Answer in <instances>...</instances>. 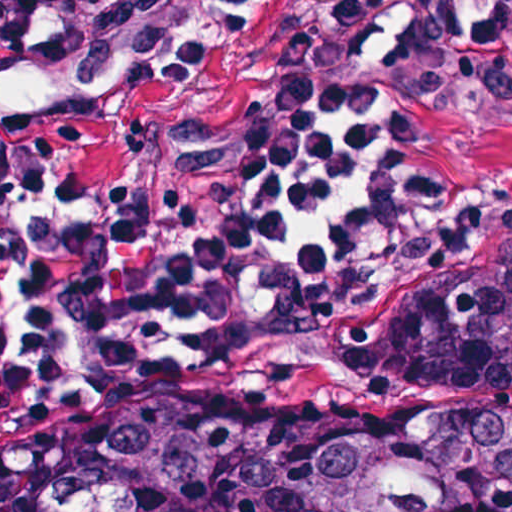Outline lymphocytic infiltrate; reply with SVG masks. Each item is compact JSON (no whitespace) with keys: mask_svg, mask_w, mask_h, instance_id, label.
Instances as JSON below:
<instances>
[{"mask_svg":"<svg viewBox=\"0 0 512 512\" xmlns=\"http://www.w3.org/2000/svg\"><path fill=\"white\" fill-rule=\"evenodd\" d=\"M179 0H0V61L38 43L100 62L167 37ZM390 138L360 112L294 124L190 201L83 198L72 121L0 82V378L80 369L146 336L233 333L350 256L374 223Z\"/></svg>","mask_w":512,"mask_h":512,"instance_id":"lymphocytic-infiltrate-1","label":"lymphocytic infiltrate"}]
</instances>
